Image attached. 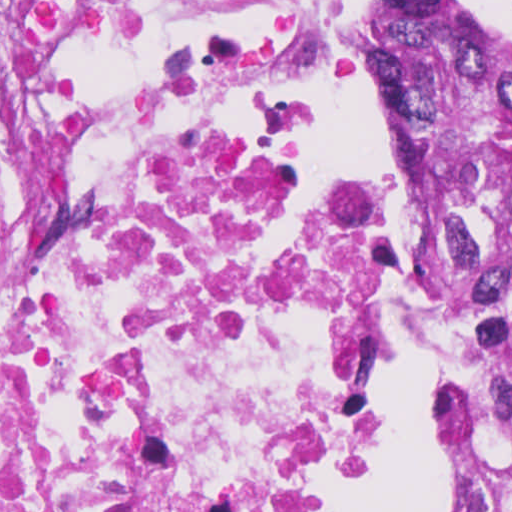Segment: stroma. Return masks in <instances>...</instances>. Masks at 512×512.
I'll use <instances>...</instances> for the list:
<instances>
[{
    "instance_id": "stroma-1",
    "label": "stroma",
    "mask_w": 512,
    "mask_h": 512,
    "mask_svg": "<svg viewBox=\"0 0 512 512\" xmlns=\"http://www.w3.org/2000/svg\"><path fill=\"white\" fill-rule=\"evenodd\" d=\"M468 1L482 11L491 33L512 57V0ZM338 2L344 15V67L342 77L369 82L386 130L402 154L395 128L384 69L370 46V6L373 0H338ZM413 187L424 262L432 282V307L438 338V383L445 420V467L446 417L454 383V332L438 286L430 240L437 214L425 203L414 182ZM392 436L393 362L392 424L378 459L369 490L372 488L386 463L390 453Z\"/></svg>"
}]
</instances>
